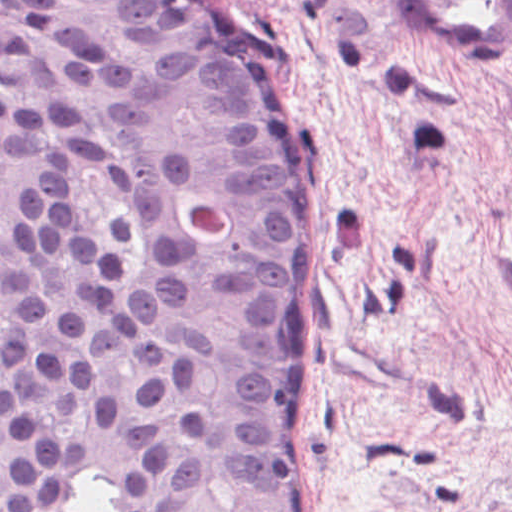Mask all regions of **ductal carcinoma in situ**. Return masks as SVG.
Returning a JSON list of instances; mask_svg holds the SVG:
<instances>
[{
    "label": "ductal carcinoma in situ",
    "mask_w": 512,
    "mask_h": 512,
    "mask_svg": "<svg viewBox=\"0 0 512 512\" xmlns=\"http://www.w3.org/2000/svg\"><path fill=\"white\" fill-rule=\"evenodd\" d=\"M320 203L201 0H0V512H312Z\"/></svg>",
    "instance_id": "1"
}]
</instances>
